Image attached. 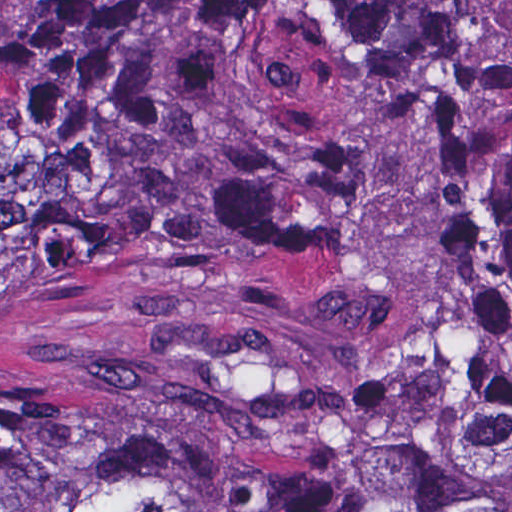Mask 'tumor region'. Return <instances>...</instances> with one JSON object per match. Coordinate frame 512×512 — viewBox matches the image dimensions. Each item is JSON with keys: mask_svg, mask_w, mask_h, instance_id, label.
Masks as SVG:
<instances>
[{"mask_svg": "<svg viewBox=\"0 0 512 512\" xmlns=\"http://www.w3.org/2000/svg\"><path fill=\"white\" fill-rule=\"evenodd\" d=\"M0 512H512V0L0 29Z\"/></svg>", "mask_w": 512, "mask_h": 512, "instance_id": "obj_1", "label": "tumor region"}]
</instances>
